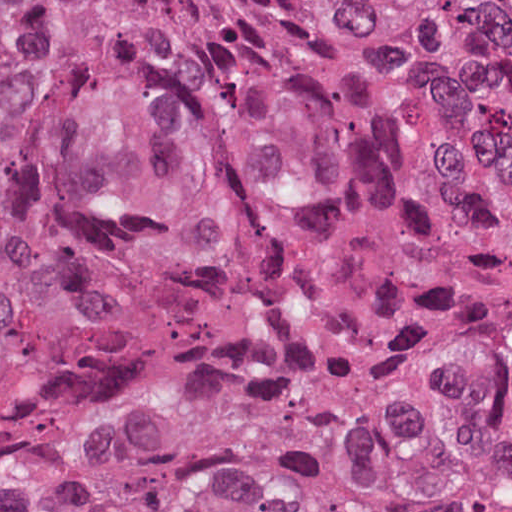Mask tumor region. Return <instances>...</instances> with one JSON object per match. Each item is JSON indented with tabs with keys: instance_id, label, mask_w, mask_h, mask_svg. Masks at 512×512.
<instances>
[{
	"instance_id": "obj_1",
	"label": "tumor region",
	"mask_w": 512,
	"mask_h": 512,
	"mask_svg": "<svg viewBox=\"0 0 512 512\" xmlns=\"http://www.w3.org/2000/svg\"><path fill=\"white\" fill-rule=\"evenodd\" d=\"M231 94L339 232L462 256L512 202V0H102ZM53 194L0 354V512H512V275L351 262L92 9L50 18ZM19 19L0 0V286Z\"/></svg>"
}]
</instances>
